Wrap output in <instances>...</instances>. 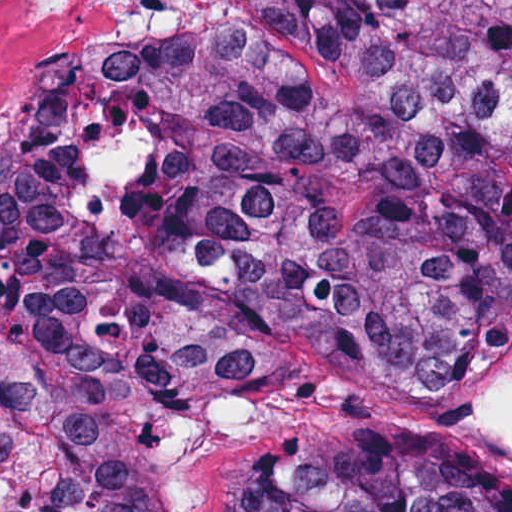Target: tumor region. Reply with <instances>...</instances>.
<instances>
[{"label": "tumor region", "instance_id": "obj_1", "mask_svg": "<svg viewBox=\"0 0 512 512\" xmlns=\"http://www.w3.org/2000/svg\"><path fill=\"white\" fill-rule=\"evenodd\" d=\"M512 341V0H187L0 151V512H176L301 352ZM218 512H512L470 446L308 430Z\"/></svg>", "mask_w": 512, "mask_h": 512}]
</instances>
